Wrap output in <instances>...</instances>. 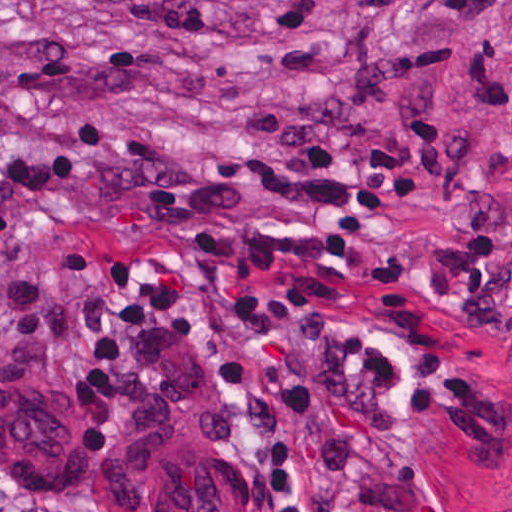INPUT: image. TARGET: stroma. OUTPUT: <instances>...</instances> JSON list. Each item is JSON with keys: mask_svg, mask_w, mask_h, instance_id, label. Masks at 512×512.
<instances>
[{"mask_svg": "<svg viewBox=\"0 0 512 512\" xmlns=\"http://www.w3.org/2000/svg\"><path fill=\"white\" fill-rule=\"evenodd\" d=\"M166 260L380 327L423 445L394 512H512V0H0V456L93 507L88 451L187 369L269 512L238 383L118 310Z\"/></svg>", "mask_w": 512, "mask_h": 512, "instance_id": "obj_1", "label": "stroma"}]
</instances>
